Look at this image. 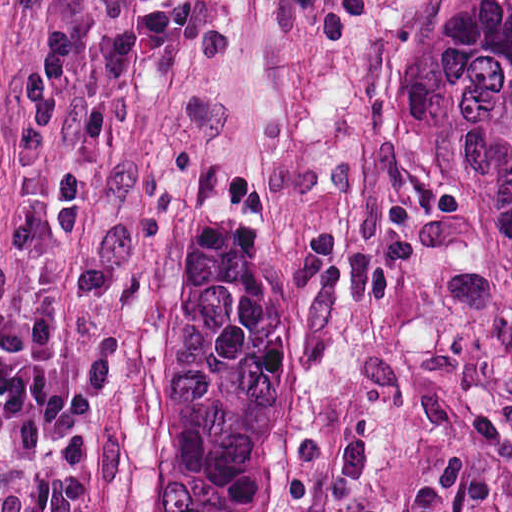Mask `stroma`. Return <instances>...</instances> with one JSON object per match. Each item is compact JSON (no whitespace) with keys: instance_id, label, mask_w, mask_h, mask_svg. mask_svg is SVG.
Masks as SVG:
<instances>
[{"instance_id":"stroma-1","label":"stroma","mask_w":512,"mask_h":512,"mask_svg":"<svg viewBox=\"0 0 512 512\" xmlns=\"http://www.w3.org/2000/svg\"><path fill=\"white\" fill-rule=\"evenodd\" d=\"M198 29L120 97L87 76L144 0H0V265L26 335L93 363L92 512H144L173 247L188 202L307 277V410L287 441V512L310 453H370L355 512H512V252L451 196L404 181L383 144V53L421 0H369L329 52L286 0H200ZM55 24L78 80L60 147L86 189L57 241L12 121Z\"/></svg>"}]
</instances>
